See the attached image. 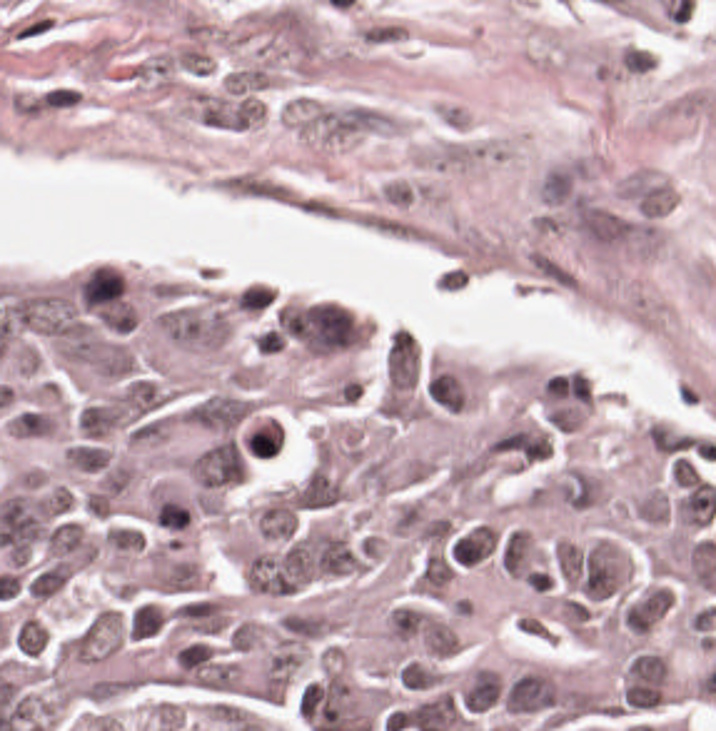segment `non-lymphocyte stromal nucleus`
<instances>
[{"label":"non-lymphocyte stromal nucleus","instance_id":"1","mask_svg":"<svg viewBox=\"0 0 716 731\" xmlns=\"http://www.w3.org/2000/svg\"><path fill=\"white\" fill-rule=\"evenodd\" d=\"M14 118L43 120L78 108L83 96L78 82L60 77H34L2 93Z\"/></svg>","mask_w":716,"mask_h":731}]
</instances>
